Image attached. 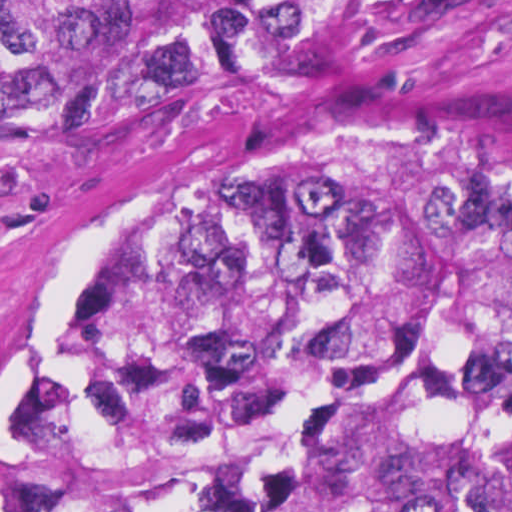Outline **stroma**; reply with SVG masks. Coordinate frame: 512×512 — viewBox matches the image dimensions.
<instances>
[{
	"label": "stroma",
	"mask_w": 512,
	"mask_h": 512,
	"mask_svg": "<svg viewBox=\"0 0 512 512\" xmlns=\"http://www.w3.org/2000/svg\"><path fill=\"white\" fill-rule=\"evenodd\" d=\"M333 132L443 135L512 165V0H378L16 160L0 183V401L111 238L273 144Z\"/></svg>",
	"instance_id": "stroma-1"
}]
</instances>
